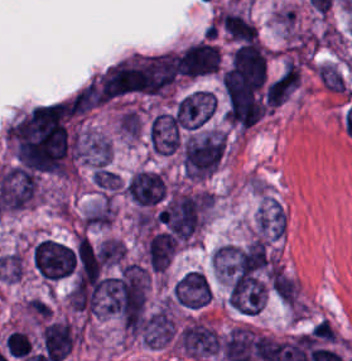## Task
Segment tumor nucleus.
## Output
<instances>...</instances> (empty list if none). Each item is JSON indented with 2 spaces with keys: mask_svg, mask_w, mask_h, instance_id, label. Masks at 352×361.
Returning <instances> with one entry per match:
<instances>
[{
  "mask_svg": "<svg viewBox=\"0 0 352 361\" xmlns=\"http://www.w3.org/2000/svg\"><path fill=\"white\" fill-rule=\"evenodd\" d=\"M216 98L212 91L197 88L178 97L173 105L175 125L194 130L207 122L215 107Z\"/></svg>",
  "mask_w": 352,
  "mask_h": 361,
  "instance_id": "tumor-nucleus-2",
  "label": "tumor nucleus"
},
{
  "mask_svg": "<svg viewBox=\"0 0 352 361\" xmlns=\"http://www.w3.org/2000/svg\"><path fill=\"white\" fill-rule=\"evenodd\" d=\"M81 157L96 169H106L109 164L111 143L104 135L84 133L78 142Z\"/></svg>",
  "mask_w": 352,
  "mask_h": 361,
  "instance_id": "tumor-nucleus-7",
  "label": "tumor nucleus"
},
{
  "mask_svg": "<svg viewBox=\"0 0 352 361\" xmlns=\"http://www.w3.org/2000/svg\"><path fill=\"white\" fill-rule=\"evenodd\" d=\"M219 49L207 40L189 43L177 58V72L199 76L216 72Z\"/></svg>",
  "mask_w": 352,
  "mask_h": 361,
  "instance_id": "tumor-nucleus-3",
  "label": "tumor nucleus"
},
{
  "mask_svg": "<svg viewBox=\"0 0 352 361\" xmlns=\"http://www.w3.org/2000/svg\"><path fill=\"white\" fill-rule=\"evenodd\" d=\"M172 295L183 307H203L210 296L207 276L200 270H187L174 282Z\"/></svg>",
  "mask_w": 352,
  "mask_h": 361,
  "instance_id": "tumor-nucleus-4",
  "label": "tumor nucleus"
},
{
  "mask_svg": "<svg viewBox=\"0 0 352 361\" xmlns=\"http://www.w3.org/2000/svg\"><path fill=\"white\" fill-rule=\"evenodd\" d=\"M203 192L174 190L156 213V218L174 240L188 241L200 226Z\"/></svg>",
  "mask_w": 352,
  "mask_h": 361,
  "instance_id": "tumor-nucleus-1",
  "label": "tumor nucleus"
},
{
  "mask_svg": "<svg viewBox=\"0 0 352 361\" xmlns=\"http://www.w3.org/2000/svg\"><path fill=\"white\" fill-rule=\"evenodd\" d=\"M217 20L227 38L247 41L256 39L255 25L239 14L221 10Z\"/></svg>",
  "mask_w": 352,
  "mask_h": 361,
  "instance_id": "tumor-nucleus-9",
  "label": "tumor nucleus"
},
{
  "mask_svg": "<svg viewBox=\"0 0 352 361\" xmlns=\"http://www.w3.org/2000/svg\"><path fill=\"white\" fill-rule=\"evenodd\" d=\"M124 192L135 203L154 204L165 194V181L151 170H138L128 179Z\"/></svg>",
  "mask_w": 352,
  "mask_h": 361,
  "instance_id": "tumor-nucleus-5",
  "label": "tumor nucleus"
},
{
  "mask_svg": "<svg viewBox=\"0 0 352 361\" xmlns=\"http://www.w3.org/2000/svg\"><path fill=\"white\" fill-rule=\"evenodd\" d=\"M173 236L164 231L150 235L146 244V260L154 270H164L175 251Z\"/></svg>",
  "mask_w": 352,
  "mask_h": 361,
  "instance_id": "tumor-nucleus-8",
  "label": "tumor nucleus"
},
{
  "mask_svg": "<svg viewBox=\"0 0 352 361\" xmlns=\"http://www.w3.org/2000/svg\"><path fill=\"white\" fill-rule=\"evenodd\" d=\"M44 353L52 361H59L71 349L74 339L72 328L65 321H52L40 331Z\"/></svg>",
  "mask_w": 352,
  "mask_h": 361,
  "instance_id": "tumor-nucleus-6",
  "label": "tumor nucleus"
}]
</instances>
